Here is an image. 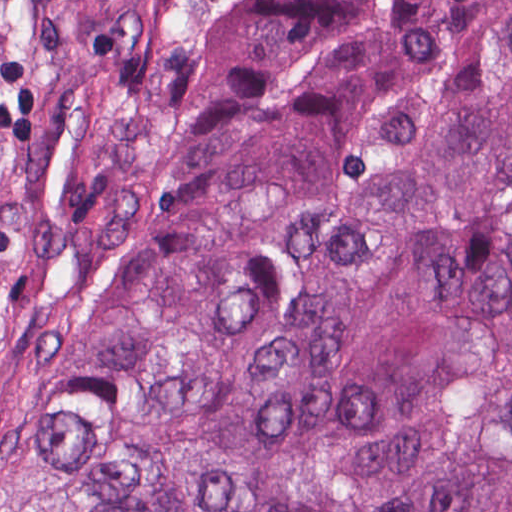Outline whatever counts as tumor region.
Masks as SVG:
<instances>
[{
	"instance_id": "obj_1",
	"label": "tumor region",
	"mask_w": 512,
	"mask_h": 512,
	"mask_svg": "<svg viewBox=\"0 0 512 512\" xmlns=\"http://www.w3.org/2000/svg\"><path fill=\"white\" fill-rule=\"evenodd\" d=\"M0 512H512V0H0Z\"/></svg>"
}]
</instances>
